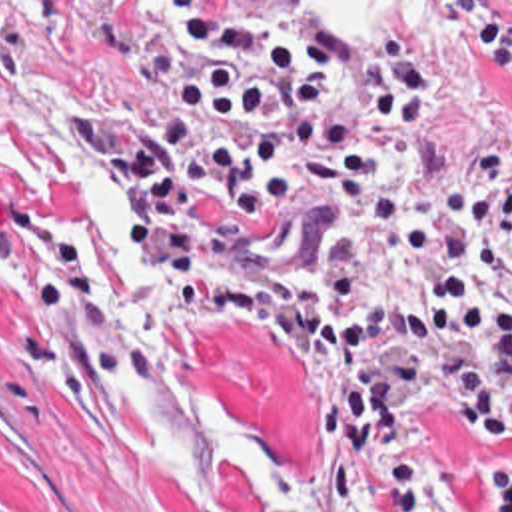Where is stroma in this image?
Listing matches in <instances>:
<instances>
[{"label": "stroma", "mask_w": 512, "mask_h": 512, "mask_svg": "<svg viewBox=\"0 0 512 512\" xmlns=\"http://www.w3.org/2000/svg\"><path fill=\"white\" fill-rule=\"evenodd\" d=\"M299 2L223 0V10L291 20ZM384 36L438 68L446 126L410 144L390 184L291 190L277 226L281 252L295 258H380L398 246L402 214L430 220L438 248L358 290L370 310L452 278L490 280L512 254V94L496 66L450 26L444 0ZM197 48L167 20L163 0H0V512H281L239 477L183 487L149 462L117 388L113 256L83 194L25 182L33 90L59 88L87 122L129 116L147 158V136ZM488 288L512 300V290ZM177 326L203 394L259 454L326 479L305 394L281 382L257 336L181 318ZM408 444L432 462L430 512L490 503L478 469L508 444L480 448L450 410L416 412ZM350 467L368 511V469L358 456Z\"/></svg>", "instance_id": "stroma-1"}]
</instances>
